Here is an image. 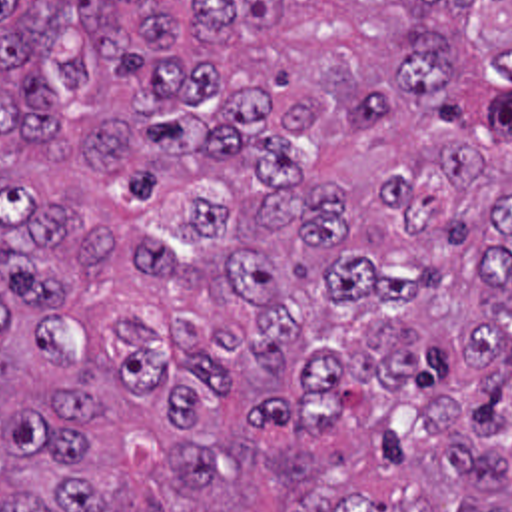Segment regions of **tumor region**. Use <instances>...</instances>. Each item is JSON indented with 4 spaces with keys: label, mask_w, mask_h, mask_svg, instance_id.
<instances>
[{
    "label": "tumor region",
    "mask_w": 512,
    "mask_h": 512,
    "mask_svg": "<svg viewBox=\"0 0 512 512\" xmlns=\"http://www.w3.org/2000/svg\"><path fill=\"white\" fill-rule=\"evenodd\" d=\"M0 512H512V0H0Z\"/></svg>",
    "instance_id": "1"
}]
</instances>
